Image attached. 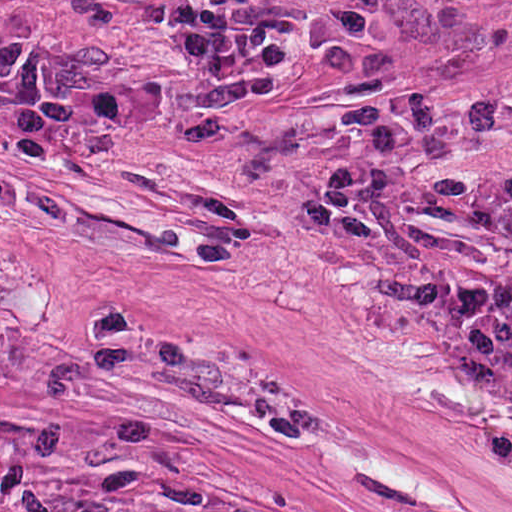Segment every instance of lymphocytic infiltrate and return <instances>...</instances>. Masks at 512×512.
<instances>
[{"label":"lymphocytic infiltrate","mask_w":512,"mask_h":512,"mask_svg":"<svg viewBox=\"0 0 512 512\" xmlns=\"http://www.w3.org/2000/svg\"><path fill=\"white\" fill-rule=\"evenodd\" d=\"M0 106L58 139L115 144L174 101L0 17ZM385 282L375 307L512 432V214L365 176L320 183L304 215Z\"/></svg>","instance_id":"f902f5d3"}]
</instances>
